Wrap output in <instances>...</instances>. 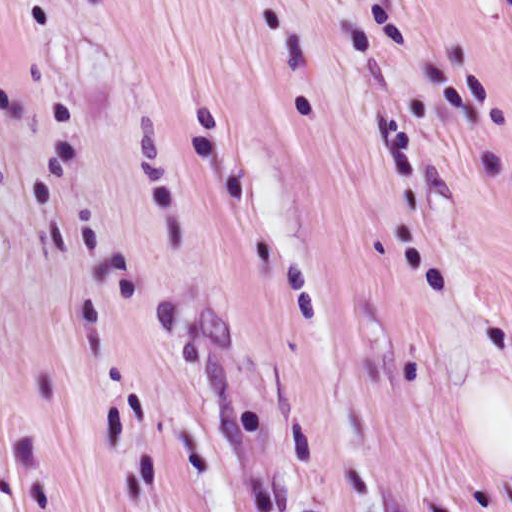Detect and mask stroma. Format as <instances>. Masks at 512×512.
<instances>
[{
    "label": "stroma",
    "mask_w": 512,
    "mask_h": 512,
    "mask_svg": "<svg viewBox=\"0 0 512 512\" xmlns=\"http://www.w3.org/2000/svg\"><path fill=\"white\" fill-rule=\"evenodd\" d=\"M0 512H512L483 0H0Z\"/></svg>",
    "instance_id": "stroma-1"
}]
</instances>
